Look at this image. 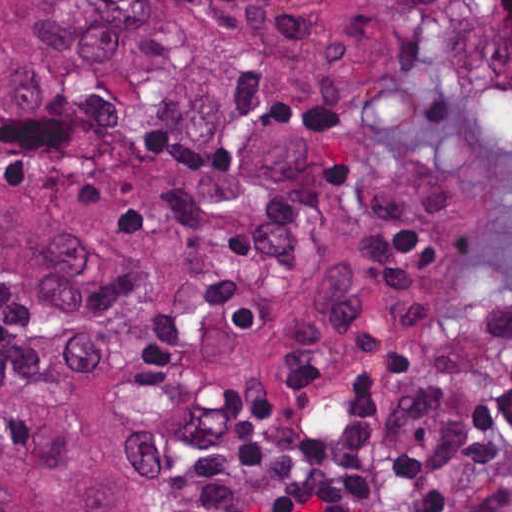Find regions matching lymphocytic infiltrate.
Wrapping results in <instances>:
<instances>
[{"label":"lymphocytic infiltrate","instance_id":"obj_1","mask_svg":"<svg viewBox=\"0 0 512 512\" xmlns=\"http://www.w3.org/2000/svg\"><path fill=\"white\" fill-rule=\"evenodd\" d=\"M494 396L415 385L219 512H399L405 500L422 512H512V394Z\"/></svg>","mask_w":512,"mask_h":512}]
</instances>
